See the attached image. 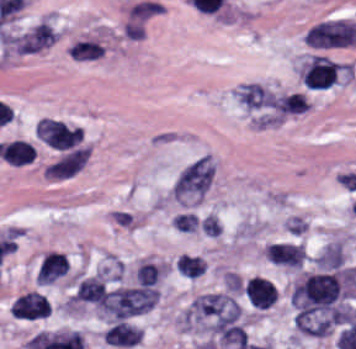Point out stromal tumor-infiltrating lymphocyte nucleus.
I'll list each match as a JSON object with an SVG mask.
<instances>
[{
    "instance_id": "obj_5",
    "label": "stromal tumor-infiltrating lymphocyte nucleus",
    "mask_w": 356,
    "mask_h": 349,
    "mask_svg": "<svg viewBox=\"0 0 356 349\" xmlns=\"http://www.w3.org/2000/svg\"><path fill=\"white\" fill-rule=\"evenodd\" d=\"M5 162L12 166L30 163L35 157V146L21 139L8 141L1 150Z\"/></svg>"
},
{
    "instance_id": "obj_3",
    "label": "stromal tumor-infiltrating lymphocyte nucleus",
    "mask_w": 356,
    "mask_h": 349,
    "mask_svg": "<svg viewBox=\"0 0 356 349\" xmlns=\"http://www.w3.org/2000/svg\"><path fill=\"white\" fill-rule=\"evenodd\" d=\"M69 271L67 256L49 252L41 261L36 274L39 284L54 282Z\"/></svg>"
},
{
    "instance_id": "obj_4",
    "label": "stromal tumor-infiltrating lymphocyte nucleus",
    "mask_w": 356,
    "mask_h": 349,
    "mask_svg": "<svg viewBox=\"0 0 356 349\" xmlns=\"http://www.w3.org/2000/svg\"><path fill=\"white\" fill-rule=\"evenodd\" d=\"M141 333L140 328L119 319L104 331L103 338L109 345L133 346Z\"/></svg>"
},
{
    "instance_id": "obj_1",
    "label": "stromal tumor-infiltrating lymphocyte nucleus",
    "mask_w": 356,
    "mask_h": 349,
    "mask_svg": "<svg viewBox=\"0 0 356 349\" xmlns=\"http://www.w3.org/2000/svg\"><path fill=\"white\" fill-rule=\"evenodd\" d=\"M10 311L18 319L35 320L50 315L51 305L42 293L30 291L18 296Z\"/></svg>"
},
{
    "instance_id": "obj_2",
    "label": "stromal tumor-infiltrating lymphocyte nucleus",
    "mask_w": 356,
    "mask_h": 349,
    "mask_svg": "<svg viewBox=\"0 0 356 349\" xmlns=\"http://www.w3.org/2000/svg\"><path fill=\"white\" fill-rule=\"evenodd\" d=\"M245 295L252 308L267 309L274 304L277 289L268 280L252 276L246 283Z\"/></svg>"
}]
</instances>
